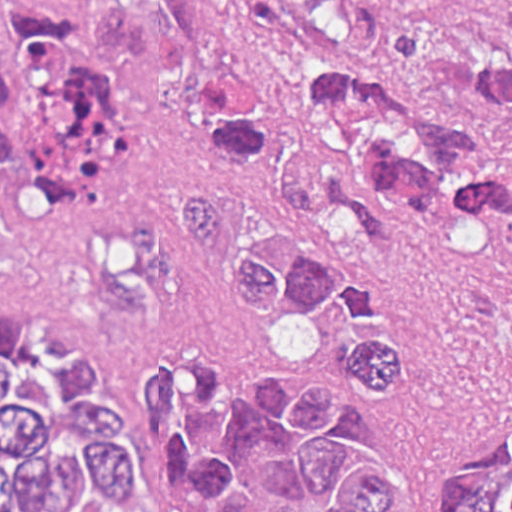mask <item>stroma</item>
<instances>
[{
	"label": "stroma",
	"instance_id": "35a3bbf8",
	"mask_svg": "<svg viewBox=\"0 0 512 512\" xmlns=\"http://www.w3.org/2000/svg\"><path fill=\"white\" fill-rule=\"evenodd\" d=\"M172 21L187 54L166 79L113 78L131 129V161L119 189L94 199L59 196L36 211L7 214V259L0 313H49L75 325L102 353L114 390L133 411L160 512H175L167 470L141 419L137 350L145 313L102 309L83 274L99 233L143 229L180 233L184 190L228 182L196 133L200 92L218 75L255 65L250 43L220 0H106ZM425 97L460 121L512 142L487 121L468 85L422 77ZM386 223L378 242L356 237L327 210L297 226L301 250L374 282L414 320L410 388H368L338 364L342 324L328 310L306 321L316 336L309 366L273 359L267 334L283 318L259 311L225 282L205 285V310L224 349L241 368L280 379L294 401L308 377L344 383L355 402L348 416L353 453L386 457L403 475L392 512H441L458 471L512 445V258L472 202L430 214L395 192L378 201ZM308 510H326L297 441L288 462L256 484V511L275 490Z\"/></svg>",
	"mask_w": 512,
	"mask_h": 512
}]
</instances>
